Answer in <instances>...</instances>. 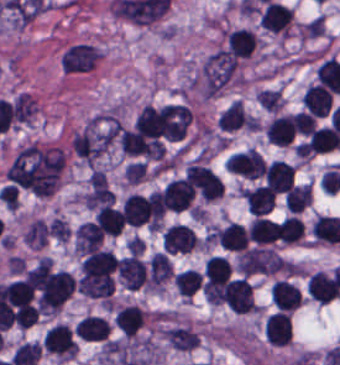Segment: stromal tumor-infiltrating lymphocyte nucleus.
<instances>
[{
	"mask_svg": "<svg viewBox=\"0 0 340 365\" xmlns=\"http://www.w3.org/2000/svg\"><path fill=\"white\" fill-rule=\"evenodd\" d=\"M201 282V274L193 268H186L173 278V285L181 296L190 297L198 288Z\"/></svg>",
	"mask_w": 340,
	"mask_h": 365,
	"instance_id": "stromal-tumor-infiltrating-lymphocyte-nucleus-30",
	"label": "stromal tumor-infiltrating lymphocyte nucleus"
},
{
	"mask_svg": "<svg viewBox=\"0 0 340 365\" xmlns=\"http://www.w3.org/2000/svg\"><path fill=\"white\" fill-rule=\"evenodd\" d=\"M47 227L42 219H35L30 222L24 235L23 242L30 247H40L45 240Z\"/></svg>",
	"mask_w": 340,
	"mask_h": 365,
	"instance_id": "stromal-tumor-infiltrating-lymphocyte-nucleus-34",
	"label": "stromal tumor-infiltrating lymphocyte nucleus"
},
{
	"mask_svg": "<svg viewBox=\"0 0 340 365\" xmlns=\"http://www.w3.org/2000/svg\"><path fill=\"white\" fill-rule=\"evenodd\" d=\"M216 239L219 246L227 251L239 252L249 243L244 226L233 221L219 228Z\"/></svg>",
	"mask_w": 340,
	"mask_h": 365,
	"instance_id": "stromal-tumor-infiltrating-lymphocyte-nucleus-16",
	"label": "stromal tumor-infiltrating lymphocyte nucleus"
},
{
	"mask_svg": "<svg viewBox=\"0 0 340 365\" xmlns=\"http://www.w3.org/2000/svg\"><path fill=\"white\" fill-rule=\"evenodd\" d=\"M206 285H220L228 281L230 265L224 256H211L204 266Z\"/></svg>",
	"mask_w": 340,
	"mask_h": 365,
	"instance_id": "stromal-tumor-infiltrating-lymphocyte-nucleus-24",
	"label": "stromal tumor-infiltrating lymphocyte nucleus"
},
{
	"mask_svg": "<svg viewBox=\"0 0 340 365\" xmlns=\"http://www.w3.org/2000/svg\"><path fill=\"white\" fill-rule=\"evenodd\" d=\"M41 345L37 341H23L17 345L10 362L12 365H31L36 362Z\"/></svg>",
	"mask_w": 340,
	"mask_h": 365,
	"instance_id": "stromal-tumor-infiltrating-lymphocyte-nucleus-32",
	"label": "stromal tumor-infiltrating lymphocyte nucleus"
},
{
	"mask_svg": "<svg viewBox=\"0 0 340 365\" xmlns=\"http://www.w3.org/2000/svg\"><path fill=\"white\" fill-rule=\"evenodd\" d=\"M243 198L249 212L263 215L274 206L276 194L265 185L244 189Z\"/></svg>",
	"mask_w": 340,
	"mask_h": 365,
	"instance_id": "stromal-tumor-infiltrating-lymphocyte-nucleus-13",
	"label": "stromal tumor-infiltrating lymphocyte nucleus"
},
{
	"mask_svg": "<svg viewBox=\"0 0 340 365\" xmlns=\"http://www.w3.org/2000/svg\"><path fill=\"white\" fill-rule=\"evenodd\" d=\"M276 222L269 217L255 216L248 226V239L258 244L275 242Z\"/></svg>",
	"mask_w": 340,
	"mask_h": 365,
	"instance_id": "stromal-tumor-infiltrating-lymphocyte-nucleus-21",
	"label": "stromal tumor-infiltrating lymphocyte nucleus"
},
{
	"mask_svg": "<svg viewBox=\"0 0 340 365\" xmlns=\"http://www.w3.org/2000/svg\"><path fill=\"white\" fill-rule=\"evenodd\" d=\"M172 273L171 264L168 258L162 252L151 254L149 260V279L150 285H159L168 278Z\"/></svg>",
	"mask_w": 340,
	"mask_h": 365,
	"instance_id": "stromal-tumor-infiltrating-lymphocyte-nucleus-27",
	"label": "stromal tumor-infiltrating lymphocyte nucleus"
},
{
	"mask_svg": "<svg viewBox=\"0 0 340 365\" xmlns=\"http://www.w3.org/2000/svg\"><path fill=\"white\" fill-rule=\"evenodd\" d=\"M247 115L243 102L234 99L219 117L218 127L233 130L244 123Z\"/></svg>",
	"mask_w": 340,
	"mask_h": 365,
	"instance_id": "stromal-tumor-infiltrating-lymphocyte-nucleus-28",
	"label": "stromal tumor-infiltrating lymphocyte nucleus"
},
{
	"mask_svg": "<svg viewBox=\"0 0 340 365\" xmlns=\"http://www.w3.org/2000/svg\"><path fill=\"white\" fill-rule=\"evenodd\" d=\"M163 246L167 254L184 253L197 247V236L186 225L173 223L163 233Z\"/></svg>",
	"mask_w": 340,
	"mask_h": 365,
	"instance_id": "stromal-tumor-infiltrating-lymphocyte-nucleus-4",
	"label": "stromal tumor-infiltrating lymphocyte nucleus"
},
{
	"mask_svg": "<svg viewBox=\"0 0 340 365\" xmlns=\"http://www.w3.org/2000/svg\"><path fill=\"white\" fill-rule=\"evenodd\" d=\"M260 21L267 30L287 35L292 21V9L271 0L263 9Z\"/></svg>",
	"mask_w": 340,
	"mask_h": 365,
	"instance_id": "stromal-tumor-infiltrating-lymphocyte-nucleus-9",
	"label": "stromal tumor-infiltrating lymphocyte nucleus"
},
{
	"mask_svg": "<svg viewBox=\"0 0 340 365\" xmlns=\"http://www.w3.org/2000/svg\"><path fill=\"white\" fill-rule=\"evenodd\" d=\"M307 288L311 298L325 304L336 299L340 293L336 279L323 271L311 275Z\"/></svg>",
	"mask_w": 340,
	"mask_h": 365,
	"instance_id": "stromal-tumor-infiltrating-lymphocyte-nucleus-10",
	"label": "stromal tumor-infiltrating lymphocyte nucleus"
},
{
	"mask_svg": "<svg viewBox=\"0 0 340 365\" xmlns=\"http://www.w3.org/2000/svg\"><path fill=\"white\" fill-rule=\"evenodd\" d=\"M255 100L266 112H277L281 107L279 90L261 89L255 93Z\"/></svg>",
	"mask_w": 340,
	"mask_h": 365,
	"instance_id": "stromal-tumor-infiltrating-lymphocyte-nucleus-35",
	"label": "stromal tumor-infiltrating lymphocyte nucleus"
},
{
	"mask_svg": "<svg viewBox=\"0 0 340 365\" xmlns=\"http://www.w3.org/2000/svg\"><path fill=\"white\" fill-rule=\"evenodd\" d=\"M193 194V189L181 178L167 183L161 198L166 210L182 212L191 206Z\"/></svg>",
	"mask_w": 340,
	"mask_h": 365,
	"instance_id": "stromal-tumor-infiltrating-lymphocyte-nucleus-6",
	"label": "stromal tumor-infiltrating lymphocyte nucleus"
},
{
	"mask_svg": "<svg viewBox=\"0 0 340 365\" xmlns=\"http://www.w3.org/2000/svg\"><path fill=\"white\" fill-rule=\"evenodd\" d=\"M165 335L169 345L176 350H191L199 340L197 333L183 326L170 328Z\"/></svg>",
	"mask_w": 340,
	"mask_h": 365,
	"instance_id": "stromal-tumor-infiltrating-lymphocyte-nucleus-26",
	"label": "stromal tumor-infiltrating lymphocyte nucleus"
},
{
	"mask_svg": "<svg viewBox=\"0 0 340 365\" xmlns=\"http://www.w3.org/2000/svg\"><path fill=\"white\" fill-rule=\"evenodd\" d=\"M102 233L91 221H84L79 224L74 233V247L80 254H90L98 251Z\"/></svg>",
	"mask_w": 340,
	"mask_h": 365,
	"instance_id": "stromal-tumor-infiltrating-lymphocyte-nucleus-15",
	"label": "stromal tumor-infiltrating lymphocyte nucleus"
},
{
	"mask_svg": "<svg viewBox=\"0 0 340 365\" xmlns=\"http://www.w3.org/2000/svg\"><path fill=\"white\" fill-rule=\"evenodd\" d=\"M185 179L204 200H214L223 195L222 181L204 164L190 163Z\"/></svg>",
	"mask_w": 340,
	"mask_h": 365,
	"instance_id": "stromal-tumor-infiltrating-lymphocyte-nucleus-1",
	"label": "stromal tumor-infiltrating lymphocyte nucleus"
},
{
	"mask_svg": "<svg viewBox=\"0 0 340 365\" xmlns=\"http://www.w3.org/2000/svg\"><path fill=\"white\" fill-rule=\"evenodd\" d=\"M36 99L25 93H18L12 102V115L20 122L29 121L35 106Z\"/></svg>",
	"mask_w": 340,
	"mask_h": 365,
	"instance_id": "stromal-tumor-infiltrating-lymphocyte-nucleus-33",
	"label": "stromal tumor-infiltrating lymphocyte nucleus"
},
{
	"mask_svg": "<svg viewBox=\"0 0 340 365\" xmlns=\"http://www.w3.org/2000/svg\"><path fill=\"white\" fill-rule=\"evenodd\" d=\"M332 104L330 92L318 85L310 83L303 95L302 105L317 118H325Z\"/></svg>",
	"mask_w": 340,
	"mask_h": 365,
	"instance_id": "stromal-tumor-infiltrating-lymphocyte-nucleus-12",
	"label": "stromal tumor-infiltrating lymphocyte nucleus"
},
{
	"mask_svg": "<svg viewBox=\"0 0 340 365\" xmlns=\"http://www.w3.org/2000/svg\"><path fill=\"white\" fill-rule=\"evenodd\" d=\"M109 329L107 322L99 316L85 315L78 321L74 335L82 341H104Z\"/></svg>",
	"mask_w": 340,
	"mask_h": 365,
	"instance_id": "stromal-tumor-infiltrating-lymphocyte-nucleus-17",
	"label": "stromal tumor-infiltrating lymphocyte nucleus"
},
{
	"mask_svg": "<svg viewBox=\"0 0 340 365\" xmlns=\"http://www.w3.org/2000/svg\"><path fill=\"white\" fill-rule=\"evenodd\" d=\"M290 212H300L312 200L311 188L308 184H295L284 197Z\"/></svg>",
	"mask_w": 340,
	"mask_h": 365,
	"instance_id": "stromal-tumor-infiltrating-lymphocyte-nucleus-31",
	"label": "stromal tumor-infiltrating lymphocyte nucleus"
},
{
	"mask_svg": "<svg viewBox=\"0 0 340 365\" xmlns=\"http://www.w3.org/2000/svg\"><path fill=\"white\" fill-rule=\"evenodd\" d=\"M295 133L291 116L280 114L265 126V136L270 143L289 144Z\"/></svg>",
	"mask_w": 340,
	"mask_h": 365,
	"instance_id": "stromal-tumor-infiltrating-lymphocyte-nucleus-19",
	"label": "stromal tumor-infiltrating lymphocyte nucleus"
},
{
	"mask_svg": "<svg viewBox=\"0 0 340 365\" xmlns=\"http://www.w3.org/2000/svg\"><path fill=\"white\" fill-rule=\"evenodd\" d=\"M42 346L54 355L73 357L77 351L68 325L63 324H56L45 331Z\"/></svg>",
	"mask_w": 340,
	"mask_h": 365,
	"instance_id": "stromal-tumor-infiltrating-lymphocyte-nucleus-3",
	"label": "stromal tumor-infiltrating lymphocyte nucleus"
},
{
	"mask_svg": "<svg viewBox=\"0 0 340 365\" xmlns=\"http://www.w3.org/2000/svg\"><path fill=\"white\" fill-rule=\"evenodd\" d=\"M116 271L126 290H137L147 280L142 263L136 254L116 258Z\"/></svg>",
	"mask_w": 340,
	"mask_h": 365,
	"instance_id": "stromal-tumor-infiltrating-lymphocyte-nucleus-5",
	"label": "stromal tumor-infiltrating lymphocyte nucleus"
},
{
	"mask_svg": "<svg viewBox=\"0 0 340 365\" xmlns=\"http://www.w3.org/2000/svg\"><path fill=\"white\" fill-rule=\"evenodd\" d=\"M223 299L234 313L254 310L253 289L246 278H233L224 283Z\"/></svg>",
	"mask_w": 340,
	"mask_h": 365,
	"instance_id": "stromal-tumor-infiltrating-lymphocyte-nucleus-2",
	"label": "stromal tumor-infiltrating lymphocyte nucleus"
},
{
	"mask_svg": "<svg viewBox=\"0 0 340 365\" xmlns=\"http://www.w3.org/2000/svg\"><path fill=\"white\" fill-rule=\"evenodd\" d=\"M101 51L88 44H74L65 54L63 71H89L92 69Z\"/></svg>",
	"mask_w": 340,
	"mask_h": 365,
	"instance_id": "stromal-tumor-infiltrating-lymphocyte-nucleus-7",
	"label": "stromal tumor-infiltrating lymphocyte nucleus"
},
{
	"mask_svg": "<svg viewBox=\"0 0 340 365\" xmlns=\"http://www.w3.org/2000/svg\"><path fill=\"white\" fill-rule=\"evenodd\" d=\"M264 336L266 342L274 346L289 344L291 338L290 315L285 312L270 315L264 327Z\"/></svg>",
	"mask_w": 340,
	"mask_h": 365,
	"instance_id": "stromal-tumor-infiltrating-lymphocyte-nucleus-11",
	"label": "stromal tumor-infiltrating lymphocyte nucleus"
},
{
	"mask_svg": "<svg viewBox=\"0 0 340 365\" xmlns=\"http://www.w3.org/2000/svg\"><path fill=\"white\" fill-rule=\"evenodd\" d=\"M15 325L24 329L37 321L36 305L18 304L14 309Z\"/></svg>",
	"mask_w": 340,
	"mask_h": 365,
	"instance_id": "stromal-tumor-infiltrating-lymphocyte-nucleus-36",
	"label": "stromal tumor-infiltrating lymphocyte nucleus"
},
{
	"mask_svg": "<svg viewBox=\"0 0 340 365\" xmlns=\"http://www.w3.org/2000/svg\"><path fill=\"white\" fill-rule=\"evenodd\" d=\"M340 134L332 127H319L310 133L305 147L307 151L324 152L339 144Z\"/></svg>",
	"mask_w": 340,
	"mask_h": 365,
	"instance_id": "stromal-tumor-infiltrating-lymphocyte-nucleus-22",
	"label": "stromal tumor-infiltrating lymphocyte nucleus"
},
{
	"mask_svg": "<svg viewBox=\"0 0 340 365\" xmlns=\"http://www.w3.org/2000/svg\"><path fill=\"white\" fill-rule=\"evenodd\" d=\"M266 186L274 192H286L293 184L295 171L284 161L273 160L263 170Z\"/></svg>",
	"mask_w": 340,
	"mask_h": 365,
	"instance_id": "stromal-tumor-infiltrating-lymphocyte-nucleus-8",
	"label": "stromal tumor-infiltrating lymphocyte nucleus"
},
{
	"mask_svg": "<svg viewBox=\"0 0 340 365\" xmlns=\"http://www.w3.org/2000/svg\"><path fill=\"white\" fill-rule=\"evenodd\" d=\"M119 145L121 151L126 154H146L148 140L139 132L129 128L119 130Z\"/></svg>",
	"mask_w": 340,
	"mask_h": 365,
	"instance_id": "stromal-tumor-infiltrating-lymphocyte-nucleus-25",
	"label": "stromal tumor-infiltrating lymphocyte nucleus"
},
{
	"mask_svg": "<svg viewBox=\"0 0 340 365\" xmlns=\"http://www.w3.org/2000/svg\"><path fill=\"white\" fill-rule=\"evenodd\" d=\"M302 235V222L296 216L291 215L281 221L274 236V239L275 241L292 244L301 241Z\"/></svg>",
	"mask_w": 340,
	"mask_h": 365,
	"instance_id": "stromal-tumor-infiltrating-lymphocyte-nucleus-29",
	"label": "stromal tumor-infiltrating lymphocyte nucleus"
},
{
	"mask_svg": "<svg viewBox=\"0 0 340 365\" xmlns=\"http://www.w3.org/2000/svg\"><path fill=\"white\" fill-rule=\"evenodd\" d=\"M228 52L249 57L256 43L255 34L245 28L226 31Z\"/></svg>",
	"mask_w": 340,
	"mask_h": 365,
	"instance_id": "stromal-tumor-infiltrating-lymphocyte-nucleus-20",
	"label": "stromal tumor-infiltrating lymphocyte nucleus"
},
{
	"mask_svg": "<svg viewBox=\"0 0 340 365\" xmlns=\"http://www.w3.org/2000/svg\"><path fill=\"white\" fill-rule=\"evenodd\" d=\"M291 118L299 133L308 135L313 132L316 121L311 112L297 111Z\"/></svg>",
	"mask_w": 340,
	"mask_h": 365,
	"instance_id": "stromal-tumor-infiltrating-lymphocyte-nucleus-37",
	"label": "stromal tumor-infiltrating lymphocyte nucleus"
},
{
	"mask_svg": "<svg viewBox=\"0 0 340 365\" xmlns=\"http://www.w3.org/2000/svg\"><path fill=\"white\" fill-rule=\"evenodd\" d=\"M273 304L278 310H292L301 301L300 293L295 284L284 279H276L271 287Z\"/></svg>",
	"mask_w": 340,
	"mask_h": 365,
	"instance_id": "stromal-tumor-infiltrating-lymphocyte-nucleus-18",
	"label": "stromal tumor-infiltrating lymphocyte nucleus"
},
{
	"mask_svg": "<svg viewBox=\"0 0 340 365\" xmlns=\"http://www.w3.org/2000/svg\"><path fill=\"white\" fill-rule=\"evenodd\" d=\"M47 231L57 242H65L69 236L68 227L60 217H53L48 222Z\"/></svg>",
	"mask_w": 340,
	"mask_h": 365,
	"instance_id": "stromal-tumor-infiltrating-lymphocyte-nucleus-38",
	"label": "stromal tumor-infiltrating lymphocyte nucleus"
},
{
	"mask_svg": "<svg viewBox=\"0 0 340 365\" xmlns=\"http://www.w3.org/2000/svg\"><path fill=\"white\" fill-rule=\"evenodd\" d=\"M94 219L100 230L109 236H117L121 232V211L114 207L100 206Z\"/></svg>",
	"mask_w": 340,
	"mask_h": 365,
	"instance_id": "stromal-tumor-infiltrating-lymphocyte-nucleus-23",
	"label": "stromal tumor-infiltrating lymphocyte nucleus"
},
{
	"mask_svg": "<svg viewBox=\"0 0 340 365\" xmlns=\"http://www.w3.org/2000/svg\"><path fill=\"white\" fill-rule=\"evenodd\" d=\"M142 318L140 306L128 304L116 310L113 323L121 334L132 339L141 327Z\"/></svg>",
	"mask_w": 340,
	"mask_h": 365,
	"instance_id": "stromal-tumor-infiltrating-lymphocyte-nucleus-14",
	"label": "stromal tumor-infiltrating lymphocyte nucleus"
}]
</instances>
